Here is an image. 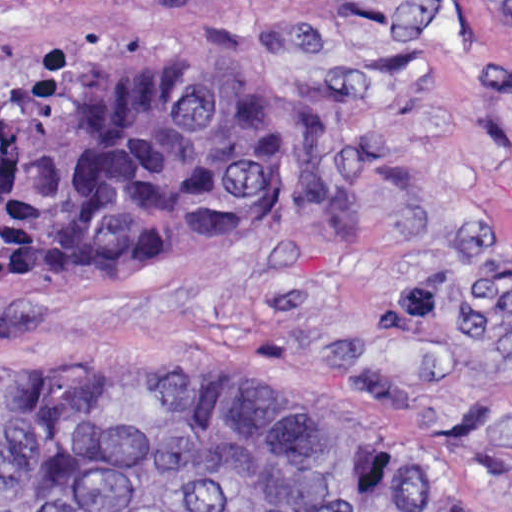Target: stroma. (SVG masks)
I'll return each instance as SVG.
<instances>
[{
	"label": "stroma",
	"mask_w": 512,
	"mask_h": 512,
	"mask_svg": "<svg viewBox=\"0 0 512 512\" xmlns=\"http://www.w3.org/2000/svg\"><path fill=\"white\" fill-rule=\"evenodd\" d=\"M178 44L287 108L255 234L10 288L0 360L299 397L512 512V0H0V98Z\"/></svg>",
	"instance_id": "35a3bbf8"
}]
</instances>
